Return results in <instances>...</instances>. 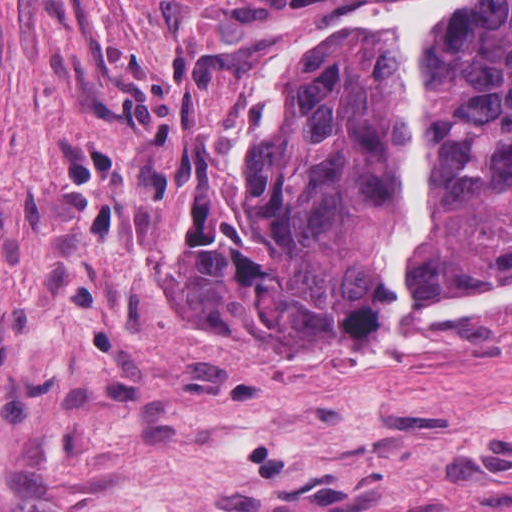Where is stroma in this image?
<instances>
[{
	"instance_id": "obj_1",
	"label": "stroma",
	"mask_w": 512,
	"mask_h": 512,
	"mask_svg": "<svg viewBox=\"0 0 512 512\" xmlns=\"http://www.w3.org/2000/svg\"><path fill=\"white\" fill-rule=\"evenodd\" d=\"M415 1L0 0L6 512H512V304L297 376L191 297L274 39Z\"/></svg>"
}]
</instances>
